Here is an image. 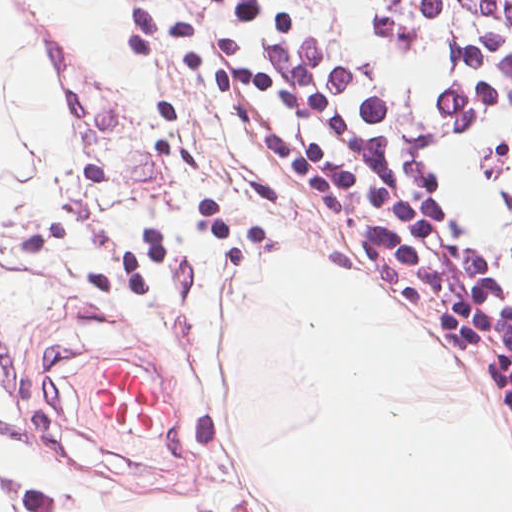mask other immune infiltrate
I'll list each match as a JSON object with an SVG mask.
<instances>
[{
	"label": "other immune infiltrate",
	"mask_w": 512,
	"mask_h": 512,
	"mask_svg": "<svg viewBox=\"0 0 512 512\" xmlns=\"http://www.w3.org/2000/svg\"><path fill=\"white\" fill-rule=\"evenodd\" d=\"M222 103L373 280L505 369L484 326L278 0H149Z\"/></svg>",
	"instance_id": "other-immune-infiltrate-1"
}]
</instances>
